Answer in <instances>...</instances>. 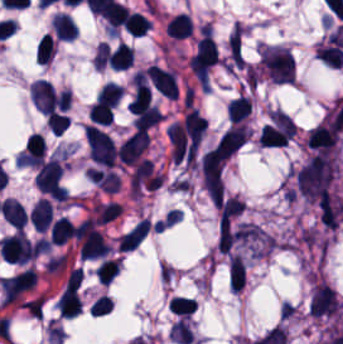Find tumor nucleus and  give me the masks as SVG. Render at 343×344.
<instances>
[{
	"instance_id": "2f306a5c",
	"label": "tumor nucleus",
	"mask_w": 343,
	"mask_h": 344,
	"mask_svg": "<svg viewBox=\"0 0 343 344\" xmlns=\"http://www.w3.org/2000/svg\"><path fill=\"white\" fill-rule=\"evenodd\" d=\"M293 174L300 193L312 202H321L330 190L335 162L326 153H319L306 160Z\"/></svg>"
},
{
	"instance_id": "2cbd58db",
	"label": "tumor nucleus",
	"mask_w": 343,
	"mask_h": 344,
	"mask_svg": "<svg viewBox=\"0 0 343 344\" xmlns=\"http://www.w3.org/2000/svg\"><path fill=\"white\" fill-rule=\"evenodd\" d=\"M148 145V132L136 129L119 143L118 159L123 163H137Z\"/></svg>"
},
{
	"instance_id": "8643909e",
	"label": "tumor nucleus",
	"mask_w": 343,
	"mask_h": 344,
	"mask_svg": "<svg viewBox=\"0 0 343 344\" xmlns=\"http://www.w3.org/2000/svg\"><path fill=\"white\" fill-rule=\"evenodd\" d=\"M84 134L91 159L110 168L118 155L113 139L94 124H86Z\"/></svg>"
},
{
	"instance_id": "5ab6c2c4",
	"label": "tumor nucleus",
	"mask_w": 343,
	"mask_h": 344,
	"mask_svg": "<svg viewBox=\"0 0 343 344\" xmlns=\"http://www.w3.org/2000/svg\"><path fill=\"white\" fill-rule=\"evenodd\" d=\"M339 301L333 289L325 282L312 288L309 309L313 316L336 313Z\"/></svg>"
}]
</instances>
